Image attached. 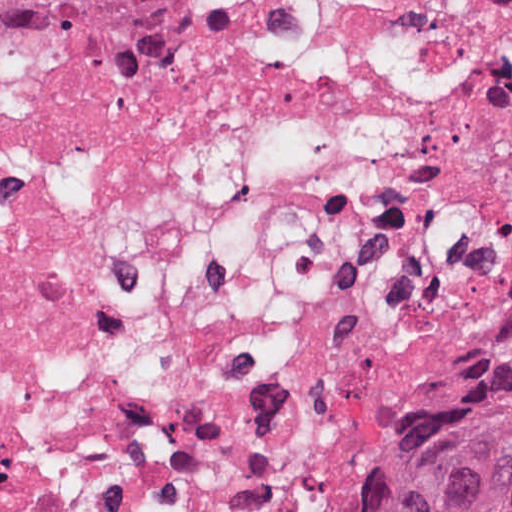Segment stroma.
<instances>
[{
  "mask_svg": "<svg viewBox=\"0 0 512 512\" xmlns=\"http://www.w3.org/2000/svg\"><path fill=\"white\" fill-rule=\"evenodd\" d=\"M242 2L228 0L221 12L198 26L225 18ZM194 28H86L55 39L20 44L0 58V95L41 60L82 50H115L177 36ZM510 350L487 357L435 389L427 409L408 427L368 483L345 501L340 512H372L379 488L398 465L474 396Z\"/></svg>",
  "mask_w": 512,
  "mask_h": 512,
  "instance_id": "1",
  "label": "stroma"
}]
</instances>
